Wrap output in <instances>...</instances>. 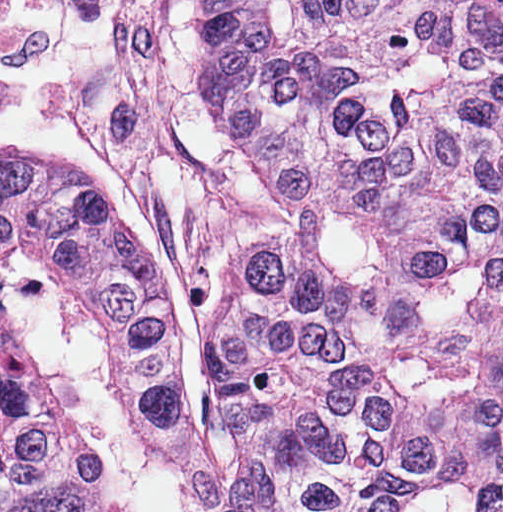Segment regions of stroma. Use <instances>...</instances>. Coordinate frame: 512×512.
<instances>
[{
	"label": "stroma",
	"instance_id": "35a3bbf8",
	"mask_svg": "<svg viewBox=\"0 0 512 512\" xmlns=\"http://www.w3.org/2000/svg\"><path fill=\"white\" fill-rule=\"evenodd\" d=\"M0 142L64 159L148 229L179 290L190 420L233 457L205 360L215 307L255 244L147 0H5Z\"/></svg>",
	"mask_w": 512,
	"mask_h": 512
}]
</instances>
